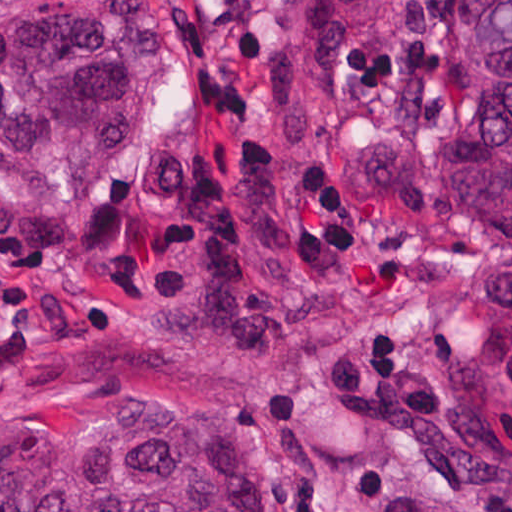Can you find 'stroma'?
Masks as SVG:
<instances>
[{
    "mask_svg": "<svg viewBox=\"0 0 512 512\" xmlns=\"http://www.w3.org/2000/svg\"><path fill=\"white\" fill-rule=\"evenodd\" d=\"M175 33L104 173L61 202L0 195V426L115 404L235 415L277 512H385L392 494L512 512L469 373L512 353V256H489L432 173L392 202L330 133L437 141L433 89L363 37L331 119L291 139L259 64L289 0H153Z\"/></svg>",
    "mask_w": 512,
    "mask_h": 512,
    "instance_id": "35a3bbf8",
    "label": "stroma"
}]
</instances>
